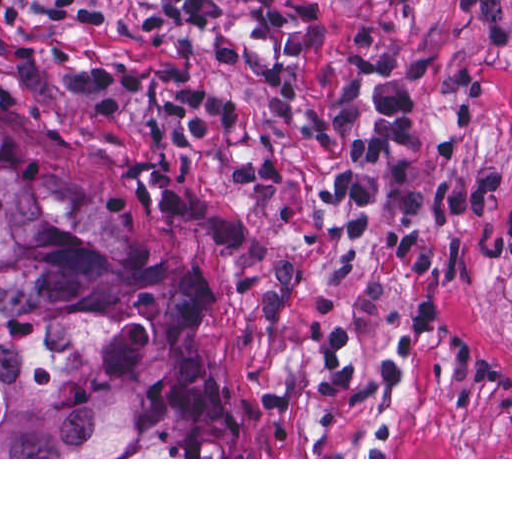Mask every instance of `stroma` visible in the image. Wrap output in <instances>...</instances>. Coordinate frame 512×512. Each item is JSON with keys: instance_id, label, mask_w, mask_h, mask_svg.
Wrapping results in <instances>:
<instances>
[{"instance_id": "obj_1", "label": "stroma", "mask_w": 512, "mask_h": 512, "mask_svg": "<svg viewBox=\"0 0 512 512\" xmlns=\"http://www.w3.org/2000/svg\"><path fill=\"white\" fill-rule=\"evenodd\" d=\"M105 5L116 0H98ZM216 30L95 29L42 0H0V116L59 174L98 192L126 234L197 270L219 381L233 394L243 457L0 459H512L511 50L447 11L448 0H217ZM362 28L398 49L443 54L423 83L416 162L389 177L424 190L447 175L505 171L480 216L434 220L432 328L419 357L391 341L399 294L370 207L354 238L315 191L339 170V134H313L347 78ZM106 63H183L197 86L247 101L280 145L283 185H238V136L181 148L144 129L159 94L116 120L75 83Z\"/></svg>"}]
</instances>
